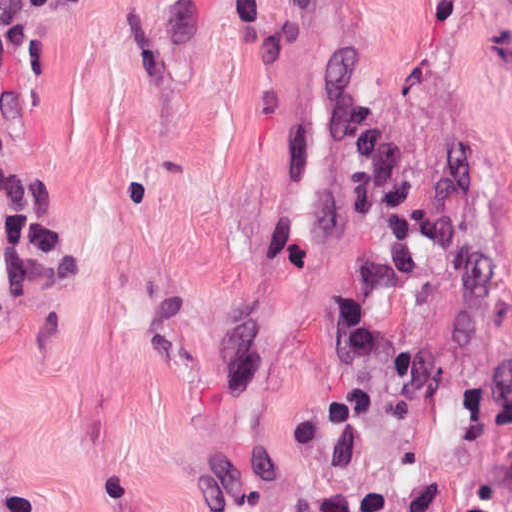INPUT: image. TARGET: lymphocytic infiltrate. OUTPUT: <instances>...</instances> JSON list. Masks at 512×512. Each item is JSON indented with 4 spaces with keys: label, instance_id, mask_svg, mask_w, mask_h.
I'll use <instances>...</instances> for the list:
<instances>
[{
    "label": "lymphocytic infiltrate",
    "instance_id": "lymphocytic-infiltrate-1",
    "mask_svg": "<svg viewBox=\"0 0 512 512\" xmlns=\"http://www.w3.org/2000/svg\"><path fill=\"white\" fill-rule=\"evenodd\" d=\"M77 200L64 184L27 181L0 166V247L21 281L54 289L76 272Z\"/></svg>",
    "mask_w": 512,
    "mask_h": 512
}]
</instances>
